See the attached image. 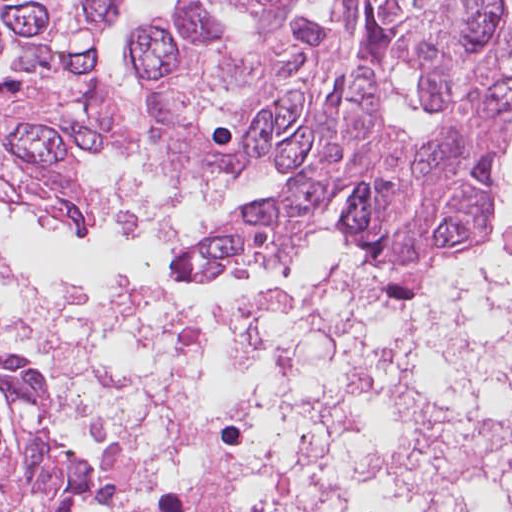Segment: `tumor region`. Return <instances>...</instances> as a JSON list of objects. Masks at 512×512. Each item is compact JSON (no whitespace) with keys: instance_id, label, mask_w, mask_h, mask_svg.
Listing matches in <instances>:
<instances>
[{"instance_id":"e687c5a6","label":"tumor region","mask_w":512,"mask_h":512,"mask_svg":"<svg viewBox=\"0 0 512 512\" xmlns=\"http://www.w3.org/2000/svg\"><path fill=\"white\" fill-rule=\"evenodd\" d=\"M512 111L293 181L204 234L182 274L256 272L290 262L305 231L328 224L360 259L399 268L471 248L490 233Z\"/></svg>"}]
</instances>
